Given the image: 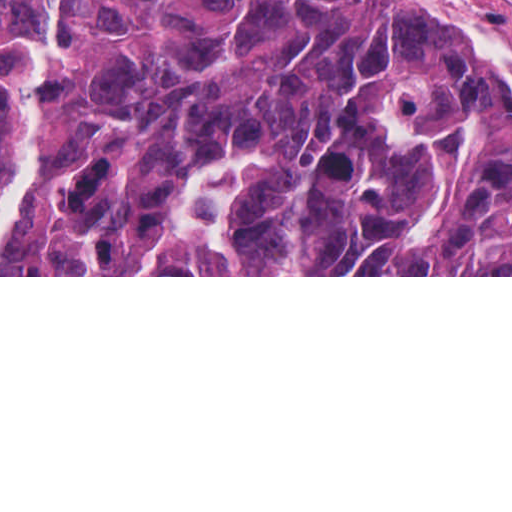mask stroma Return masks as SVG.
Returning a JSON list of instances; mask_svg holds the SVG:
<instances>
[{
  "label": "stroma",
  "instance_id": "stroma-1",
  "mask_svg": "<svg viewBox=\"0 0 512 512\" xmlns=\"http://www.w3.org/2000/svg\"><path fill=\"white\" fill-rule=\"evenodd\" d=\"M499 32L512 41V0H472ZM55 91V11H54ZM247 165V152H246ZM0 277H512V275H0Z\"/></svg>",
  "mask_w": 512,
  "mask_h": 512
}]
</instances>
